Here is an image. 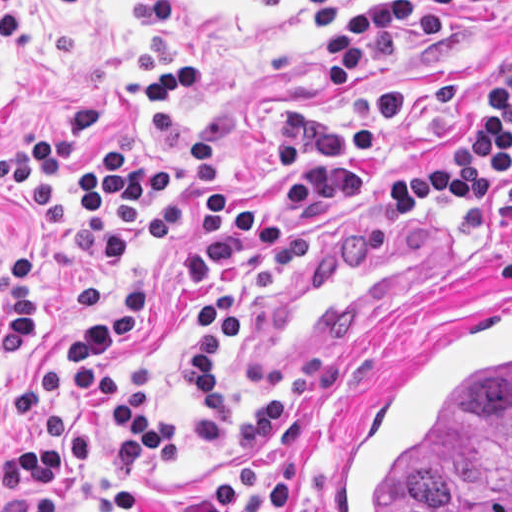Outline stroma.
I'll use <instances>...</instances> for the list:
<instances>
[{
  "label": "stroma",
  "mask_w": 512,
  "mask_h": 512,
  "mask_svg": "<svg viewBox=\"0 0 512 512\" xmlns=\"http://www.w3.org/2000/svg\"><path fill=\"white\" fill-rule=\"evenodd\" d=\"M389 0H346L320 33L311 0H0V154L23 143L77 101L145 81L132 54L151 35L169 34L179 54H198L201 83L164 108L125 96L82 139L55 187L63 226L44 229L34 210L18 214L38 282V339L23 359L0 355V463L19 448L26 422L17 386L56 370L65 395L50 412L102 432L100 459L70 488L69 512H123L122 488L170 503L198 497L233 467L250 414L276 388L277 407L296 394L304 370L342 363V382L313 403L297 437L276 458L299 463L285 512H333L347 451L410 358L437 330L479 306L512 301L499 261L512 251V216L491 199L483 222H465L431 196L417 209L382 214L379 185L418 172L428 144L457 141L464 106L482 79L512 68V0H485L448 17L424 52L366 64L344 93L324 86V39L364 8ZM401 88L405 127L379 149L354 156L359 192L329 212L311 199L287 204L306 252L267 293L230 283L244 301L234 340L222 349V398L229 432L221 442L188 428L194 403L183 386L181 349L197 321L177 281L197 236L195 177L188 140L196 131L217 149L226 188L249 211L285 194L269 166L276 122L291 105L318 101L350 117L374 92ZM128 136L147 166H173L175 194L114 223L131 237L111 261L102 238L77 225L68 173L95 161L109 140ZM13 223L0 210V276ZM156 291V307L115 344L113 371L129 394L162 418L173 457L138 449L70 379V349L59 327L98 315L119 284ZM4 495L0 487V506Z\"/></svg>",
  "instance_id": "1"
}]
</instances>
